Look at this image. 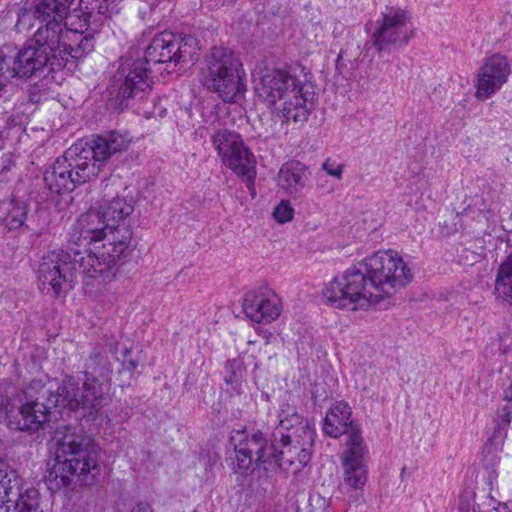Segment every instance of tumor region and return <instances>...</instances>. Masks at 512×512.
Listing matches in <instances>:
<instances>
[{
	"label": "tumor region",
	"mask_w": 512,
	"mask_h": 512,
	"mask_svg": "<svg viewBox=\"0 0 512 512\" xmlns=\"http://www.w3.org/2000/svg\"><path fill=\"white\" fill-rule=\"evenodd\" d=\"M0 512H512V0H0Z\"/></svg>",
	"instance_id": "tumor-region-1"
}]
</instances>
